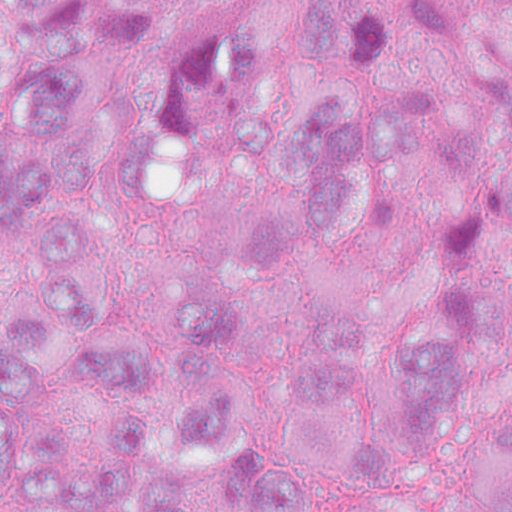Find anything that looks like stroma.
Wrapping results in <instances>:
<instances>
[{
    "label": "stroma",
    "instance_id": "1",
    "mask_svg": "<svg viewBox=\"0 0 512 512\" xmlns=\"http://www.w3.org/2000/svg\"><path fill=\"white\" fill-rule=\"evenodd\" d=\"M268 0H239V9ZM512 4V0H499ZM103 106L149 149L154 174L109 205V325L123 348L173 339L178 282L201 240L223 224V171L239 122L307 88H360L414 108L452 143L512 166V44H437L390 64H328L275 44L218 39L180 1L149 44L99 54ZM454 279H479L474 330L451 339L469 390L434 440L408 435L385 360L359 374L394 448L389 476L361 490L299 474L309 512H394L439 503L459 453L512 404V241L434 159L408 164L332 251L261 279L229 357V395L274 409L298 395L308 343L338 298L414 314ZM0 512H51L9 495Z\"/></svg>",
    "mask_w": 512,
    "mask_h": 512
}]
</instances>
